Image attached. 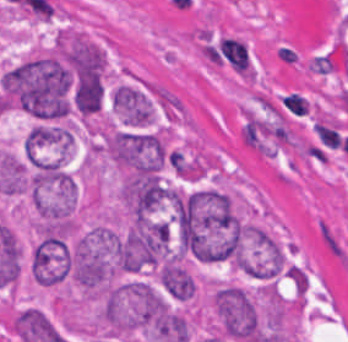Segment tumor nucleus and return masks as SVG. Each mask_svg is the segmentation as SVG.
<instances>
[{"label": "tumor nucleus", "instance_id": "4", "mask_svg": "<svg viewBox=\"0 0 348 342\" xmlns=\"http://www.w3.org/2000/svg\"><path fill=\"white\" fill-rule=\"evenodd\" d=\"M170 192L159 173L129 168L121 185L122 205L133 220L165 204Z\"/></svg>", "mask_w": 348, "mask_h": 342}, {"label": "tumor nucleus", "instance_id": "5", "mask_svg": "<svg viewBox=\"0 0 348 342\" xmlns=\"http://www.w3.org/2000/svg\"><path fill=\"white\" fill-rule=\"evenodd\" d=\"M114 113L123 124L143 126L155 115V103L149 93L134 83H121L111 94Z\"/></svg>", "mask_w": 348, "mask_h": 342}, {"label": "tumor nucleus", "instance_id": "2", "mask_svg": "<svg viewBox=\"0 0 348 342\" xmlns=\"http://www.w3.org/2000/svg\"><path fill=\"white\" fill-rule=\"evenodd\" d=\"M169 150L161 129L117 128L105 139L106 155L123 168L156 173L168 162Z\"/></svg>", "mask_w": 348, "mask_h": 342}, {"label": "tumor nucleus", "instance_id": "1", "mask_svg": "<svg viewBox=\"0 0 348 342\" xmlns=\"http://www.w3.org/2000/svg\"><path fill=\"white\" fill-rule=\"evenodd\" d=\"M171 248V229L161 219L140 216L119 234L113 267L127 271L160 263Z\"/></svg>", "mask_w": 348, "mask_h": 342}, {"label": "tumor nucleus", "instance_id": "3", "mask_svg": "<svg viewBox=\"0 0 348 342\" xmlns=\"http://www.w3.org/2000/svg\"><path fill=\"white\" fill-rule=\"evenodd\" d=\"M213 306L223 337L238 342L262 341L258 312L245 288L225 284L214 293Z\"/></svg>", "mask_w": 348, "mask_h": 342}]
</instances>
